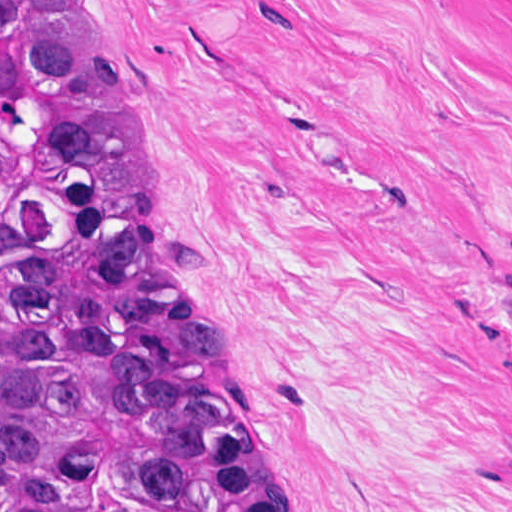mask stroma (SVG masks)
<instances>
[{"label":"stroma","instance_id":"1","mask_svg":"<svg viewBox=\"0 0 512 512\" xmlns=\"http://www.w3.org/2000/svg\"><path fill=\"white\" fill-rule=\"evenodd\" d=\"M103 1L279 511L512 512V0Z\"/></svg>","mask_w":512,"mask_h":512}]
</instances>
